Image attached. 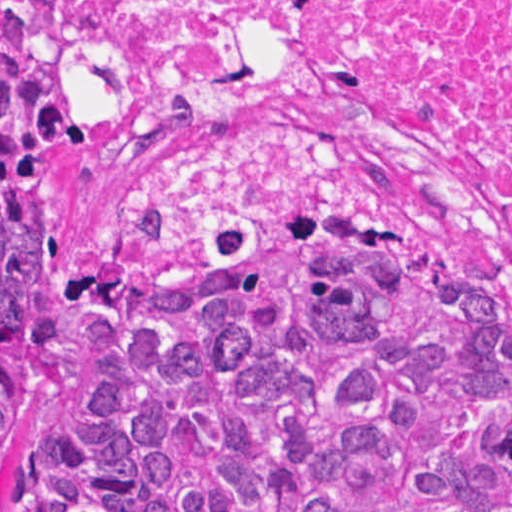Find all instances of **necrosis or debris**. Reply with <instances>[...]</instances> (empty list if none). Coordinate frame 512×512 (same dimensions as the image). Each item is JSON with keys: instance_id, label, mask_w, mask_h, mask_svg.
Returning <instances> with one entry per match:
<instances>
[{"instance_id": "necrosis-or-debris-1", "label": "necrosis or debris", "mask_w": 512, "mask_h": 512, "mask_svg": "<svg viewBox=\"0 0 512 512\" xmlns=\"http://www.w3.org/2000/svg\"><path fill=\"white\" fill-rule=\"evenodd\" d=\"M77 67L146 261L445 220L512 278V0H77Z\"/></svg>"}]
</instances>
